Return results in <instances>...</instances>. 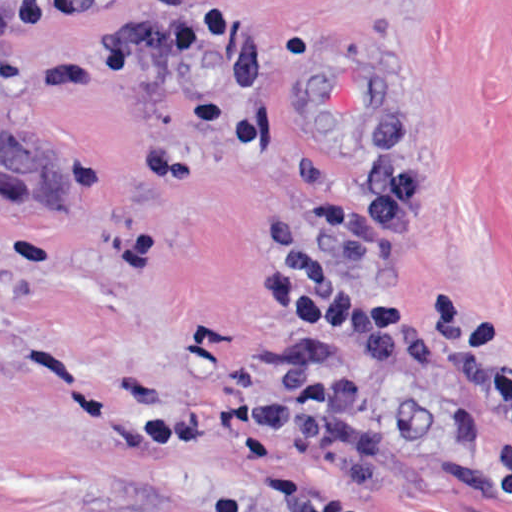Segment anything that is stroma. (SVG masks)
Here are the masks:
<instances>
[{
	"label": "stroma",
	"instance_id": "1",
	"mask_svg": "<svg viewBox=\"0 0 512 512\" xmlns=\"http://www.w3.org/2000/svg\"><path fill=\"white\" fill-rule=\"evenodd\" d=\"M399 105L418 227L393 263L512 322V0H0V512H512L509 428L339 341L379 401L351 474L279 442L140 454L144 416L249 394L289 351L260 263Z\"/></svg>",
	"mask_w": 512,
	"mask_h": 512
}]
</instances>
